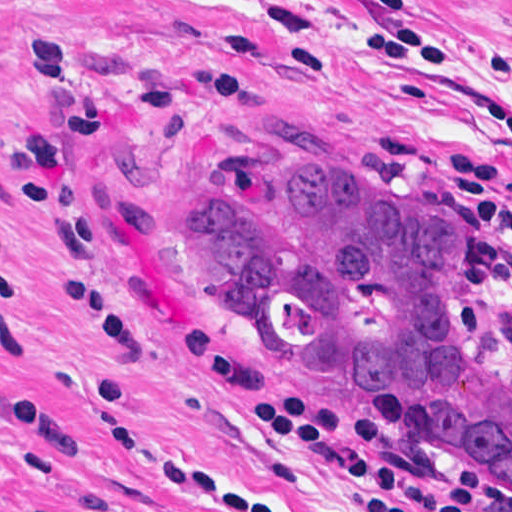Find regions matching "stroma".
Returning a JSON list of instances; mask_svg holds the SVG:
<instances>
[{"mask_svg":"<svg viewBox=\"0 0 512 512\" xmlns=\"http://www.w3.org/2000/svg\"><path fill=\"white\" fill-rule=\"evenodd\" d=\"M512 0H0V512H214L184 460L282 512H359V484L249 420L173 329L268 392L375 420L378 458L460 470L270 348L180 255L224 168H344L450 220L475 319L512 352ZM512 492L486 482L476 512Z\"/></svg>","mask_w":512,"mask_h":512,"instance_id":"obj_1","label":"stroma"}]
</instances>
